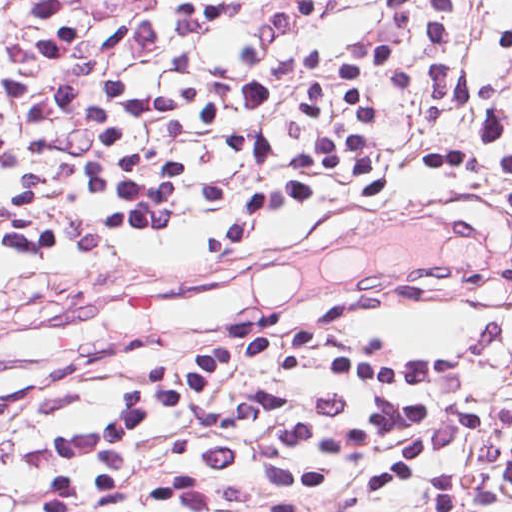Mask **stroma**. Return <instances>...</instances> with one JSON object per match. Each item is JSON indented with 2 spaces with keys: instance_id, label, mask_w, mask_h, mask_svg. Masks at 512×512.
<instances>
[{
  "instance_id": "1",
  "label": "stroma",
  "mask_w": 512,
  "mask_h": 512,
  "mask_svg": "<svg viewBox=\"0 0 512 512\" xmlns=\"http://www.w3.org/2000/svg\"><path fill=\"white\" fill-rule=\"evenodd\" d=\"M398 0H338L320 35L298 56L321 63L358 47ZM355 330L374 347H442L457 354L463 381L495 385L512 370V276L489 277L456 294H417L366 308ZM94 405V390L71 386L0 436V512H26L42 485L40 457L54 433ZM370 512H432L400 495ZM501 512H512L502 495Z\"/></svg>"
}]
</instances>
